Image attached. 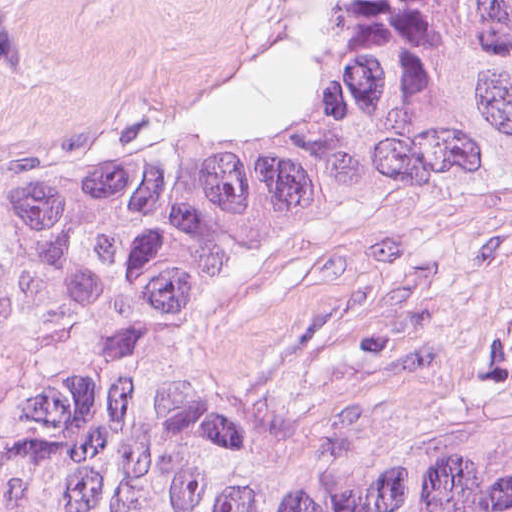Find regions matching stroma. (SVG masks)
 <instances>
[{
	"label": "stroma",
	"mask_w": 512,
	"mask_h": 512,
	"mask_svg": "<svg viewBox=\"0 0 512 512\" xmlns=\"http://www.w3.org/2000/svg\"><path fill=\"white\" fill-rule=\"evenodd\" d=\"M306 0H0V173L99 133L234 111L283 80ZM203 332L327 338L371 364L512 357V210L416 202L214 304Z\"/></svg>",
	"instance_id": "35a3bbf8"
}]
</instances>
